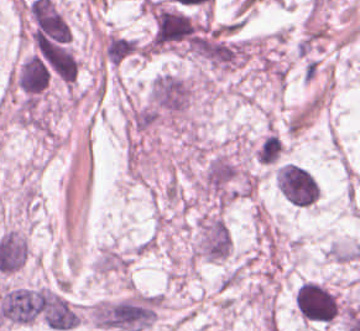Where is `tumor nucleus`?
<instances>
[{"instance_id":"obj_1","label":"tumor nucleus","mask_w":360,"mask_h":331,"mask_svg":"<svg viewBox=\"0 0 360 331\" xmlns=\"http://www.w3.org/2000/svg\"><path fill=\"white\" fill-rule=\"evenodd\" d=\"M231 250V232L227 220L220 213H200L194 231V255L206 260L227 259Z\"/></svg>"},{"instance_id":"obj_2","label":"tumor nucleus","mask_w":360,"mask_h":331,"mask_svg":"<svg viewBox=\"0 0 360 331\" xmlns=\"http://www.w3.org/2000/svg\"><path fill=\"white\" fill-rule=\"evenodd\" d=\"M278 190L292 204L309 207L319 198V185L312 171L292 161L276 167Z\"/></svg>"}]
</instances>
